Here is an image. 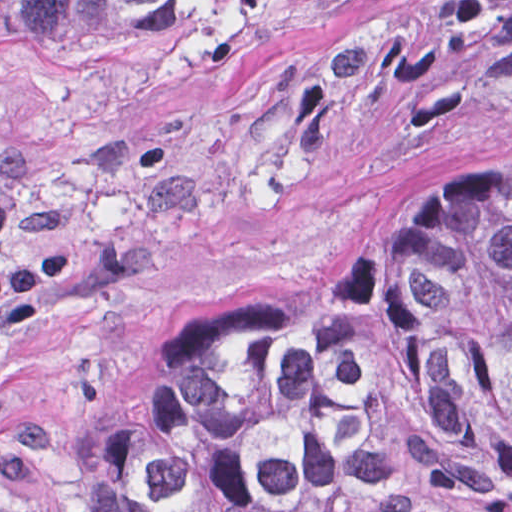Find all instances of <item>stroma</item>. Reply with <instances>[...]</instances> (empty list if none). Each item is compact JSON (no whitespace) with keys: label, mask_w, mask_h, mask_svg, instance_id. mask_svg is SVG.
I'll list each match as a JSON object with an SVG mask.
<instances>
[{"label":"stroma","mask_w":512,"mask_h":512,"mask_svg":"<svg viewBox=\"0 0 512 512\" xmlns=\"http://www.w3.org/2000/svg\"><path fill=\"white\" fill-rule=\"evenodd\" d=\"M512 163V0H246L133 44L0 31V512H97L155 344Z\"/></svg>","instance_id":"35a3bbf8"}]
</instances>
